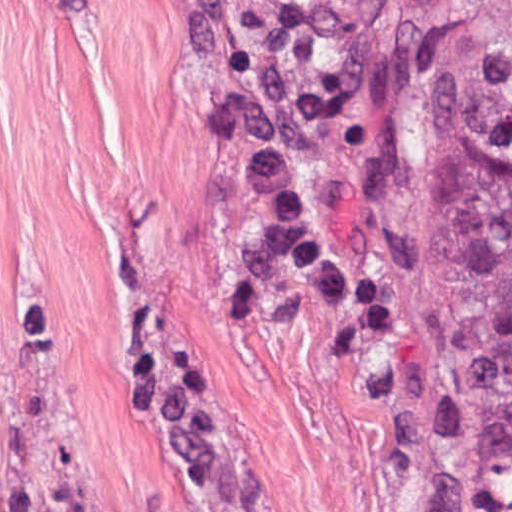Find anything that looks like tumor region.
I'll use <instances>...</instances> for the list:
<instances>
[{
  "mask_svg": "<svg viewBox=\"0 0 512 512\" xmlns=\"http://www.w3.org/2000/svg\"><path fill=\"white\" fill-rule=\"evenodd\" d=\"M428 158L453 325L491 411L493 506L512 512V0H459L428 24ZM185 512H225L168 410ZM0 512H72L0 330Z\"/></svg>",
  "mask_w": 512,
  "mask_h": 512,
  "instance_id": "tumor-region-1",
  "label": "tumor region"
}]
</instances>
